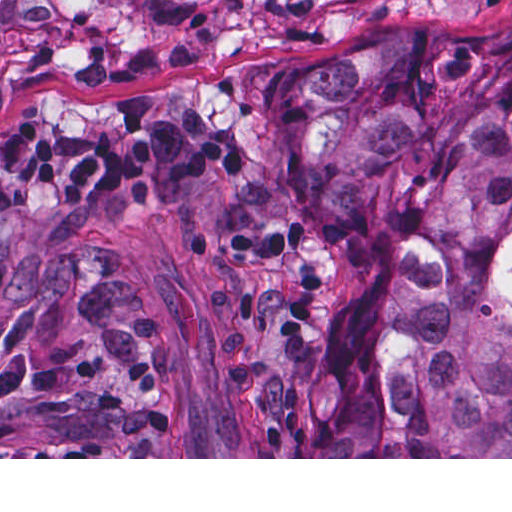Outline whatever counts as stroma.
Listing matches in <instances>:
<instances>
[{"label":"stroma","mask_w":512,"mask_h":512,"mask_svg":"<svg viewBox=\"0 0 512 512\" xmlns=\"http://www.w3.org/2000/svg\"><path fill=\"white\" fill-rule=\"evenodd\" d=\"M512 19V0H0V117L38 95L112 106L194 95L238 140L273 139L276 99L324 61L380 37ZM144 304L176 419L172 457L0 459H512L265 457L218 381L222 260L201 230L166 215L94 232ZM24 237L7 233L0 320L18 290Z\"/></svg>","instance_id":"1"}]
</instances>
